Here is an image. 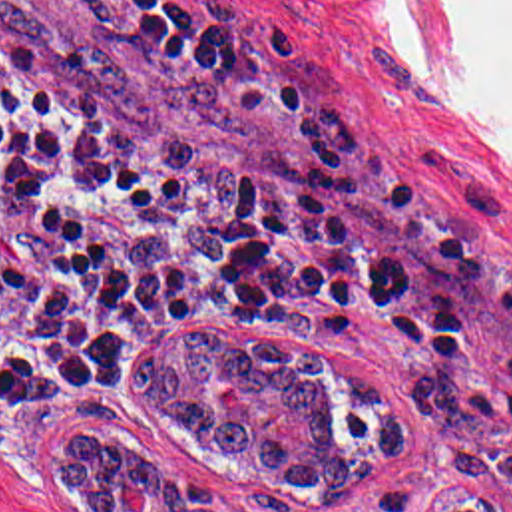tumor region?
<instances>
[{
  "instance_id": "obj_1",
  "label": "tumor region",
  "mask_w": 512,
  "mask_h": 512,
  "mask_svg": "<svg viewBox=\"0 0 512 512\" xmlns=\"http://www.w3.org/2000/svg\"><path fill=\"white\" fill-rule=\"evenodd\" d=\"M216 378H232L242 412L212 402ZM137 392L198 451L244 463L254 481L310 499H358L372 473L413 443V416L370 378L310 346L270 334L180 328L135 354ZM57 471L89 512H127L119 477L149 483V512H224L216 485L168 475L158 455L97 439H69ZM437 512V511H433ZM439 512H512L483 495L449 493Z\"/></svg>"
}]
</instances>
